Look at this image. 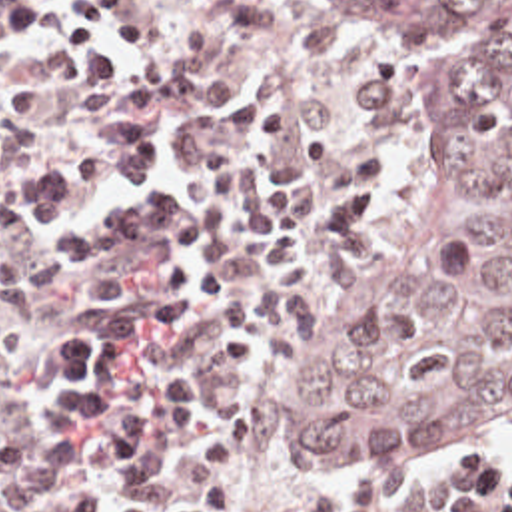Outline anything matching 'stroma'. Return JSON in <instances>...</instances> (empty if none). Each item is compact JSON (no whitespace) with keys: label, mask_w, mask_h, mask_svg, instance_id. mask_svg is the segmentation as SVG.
Segmentation results:
<instances>
[{"label":"stroma","mask_w":512,"mask_h":512,"mask_svg":"<svg viewBox=\"0 0 512 512\" xmlns=\"http://www.w3.org/2000/svg\"><path fill=\"white\" fill-rule=\"evenodd\" d=\"M1 1V0H0ZM289 9L297 19L313 21L348 41V55L386 77L392 85V123L386 133V193L370 221L343 249V265L321 285L295 335H281L259 311L261 319V367L255 373L225 375L223 357L207 329H167L145 339V353L159 367H193L211 379V415L207 423L187 428L151 450L155 464L169 482V498L185 494L195 474V454L207 432L221 415L233 409L249 411L255 419V446L241 492L237 512H289L305 500H329L354 482H412L428 464L408 468H299L281 462L267 446V421L275 397L287 389L311 363L319 343L327 301L344 279L362 265L384 241L392 225L412 201L416 185V93L404 63L390 55L380 41L348 27L341 19L317 11L299 0H253ZM149 17V45L133 49L131 79H139L167 57L197 39L205 27V0H137L131 7ZM117 45L107 35H101ZM0 85L19 89H63L73 83L67 49L55 35L53 25L27 33H5L0 27ZM127 115L153 121L171 145V171L183 185L191 163L205 151L227 149L233 159L231 179V277L237 287L251 293L249 275V221L251 187L249 157L233 135L219 123H199L183 133L169 135L157 113L115 111L97 125L81 131L47 127L29 113L0 117V135L15 127H31L41 133L43 145L7 187V215L27 237L29 259L51 277V297L27 305L19 313L23 351L0 369V440L25 434L35 446L75 440L83 468L75 484H83L93 500L91 512H121V492L109 462L95 436L87 432H59L45 421V385L55 365V331L59 323L75 317L103 313V303L93 301L87 277L75 269H55L47 263L45 245L33 237L17 219V193L23 179L49 165L65 167L79 175V143L87 135L103 133L127 159ZM155 277V267L143 271ZM456 454H484L512 468V430L498 440ZM492 508H494V464H492Z\"/></svg>","instance_id":"1"}]
</instances>
